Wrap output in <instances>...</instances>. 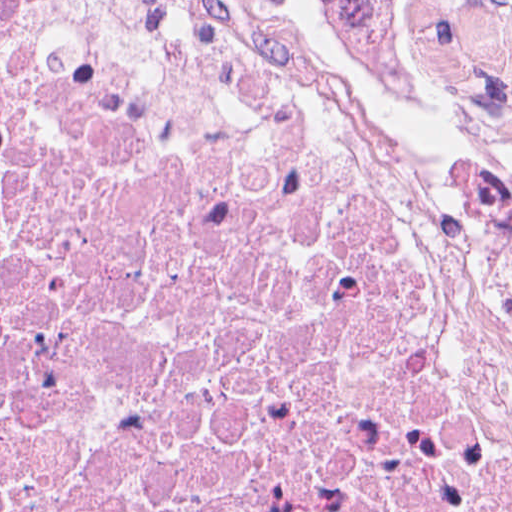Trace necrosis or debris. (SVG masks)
Segmentation results:
<instances>
[{"label": "necrosis or debris", "instance_id": "4bbe7bcc", "mask_svg": "<svg viewBox=\"0 0 512 512\" xmlns=\"http://www.w3.org/2000/svg\"><path fill=\"white\" fill-rule=\"evenodd\" d=\"M0 512H512V116L311 0H0Z\"/></svg>", "mask_w": 512, "mask_h": 512}]
</instances>
